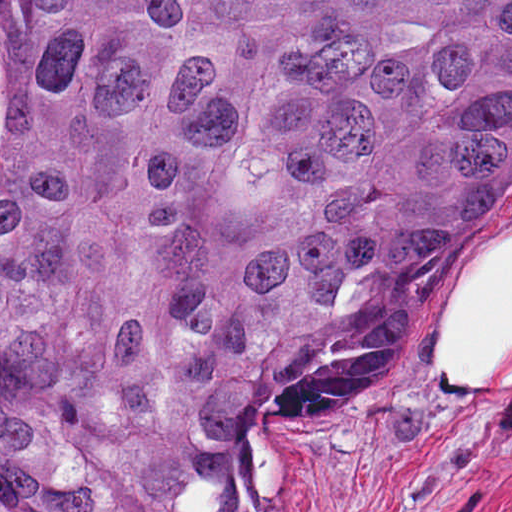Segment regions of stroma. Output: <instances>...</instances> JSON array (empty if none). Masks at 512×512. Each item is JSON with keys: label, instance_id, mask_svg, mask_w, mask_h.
Instances as JSON below:
<instances>
[{"label": "stroma", "instance_id": "1", "mask_svg": "<svg viewBox=\"0 0 512 512\" xmlns=\"http://www.w3.org/2000/svg\"><path fill=\"white\" fill-rule=\"evenodd\" d=\"M505 237L512 160L420 309L235 472L228 512H512V388H470L437 365L469 268Z\"/></svg>", "mask_w": 512, "mask_h": 512}]
</instances>
